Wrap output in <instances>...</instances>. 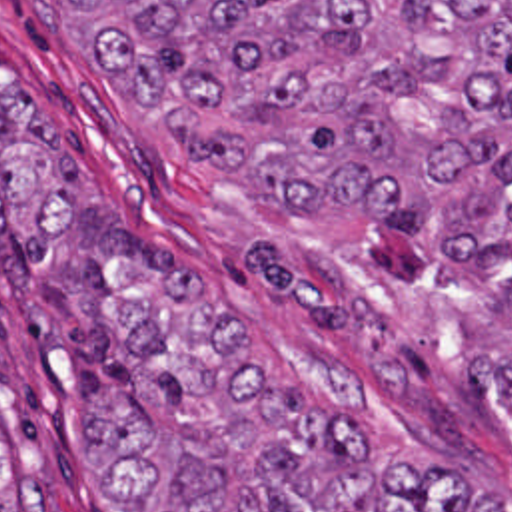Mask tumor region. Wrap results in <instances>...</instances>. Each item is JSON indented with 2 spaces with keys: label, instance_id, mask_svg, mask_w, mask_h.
<instances>
[{
  "label": "tumor region",
  "instance_id": "e687c5a6",
  "mask_svg": "<svg viewBox=\"0 0 512 512\" xmlns=\"http://www.w3.org/2000/svg\"><path fill=\"white\" fill-rule=\"evenodd\" d=\"M76 44L226 144L292 224L372 238L512 387V0H68ZM0 198L140 409H76L118 512H512V491L392 429L282 393L144 244L38 102L0 114ZM36 477L0 512H48Z\"/></svg>",
  "mask_w": 512,
  "mask_h": 512
}]
</instances>
